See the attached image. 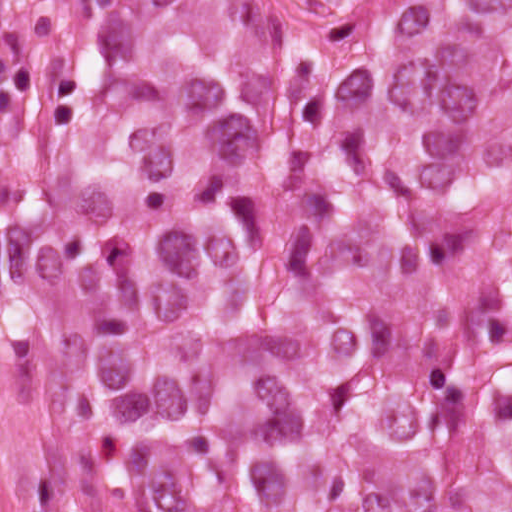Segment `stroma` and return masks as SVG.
Here are the masks:
<instances>
[{
    "mask_svg": "<svg viewBox=\"0 0 512 512\" xmlns=\"http://www.w3.org/2000/svg\"><path fill=\"white\" fill-rule=\"evenodd\" d=\"M252 33L285 0H235ZM76 89L71 0H0V512H94L59 411Z\"/></svg>",
    "mask_w": 512,
    "mask_h": 512,
    "instance_id": "1",
    "label": "stroma"
}]
</instances>
